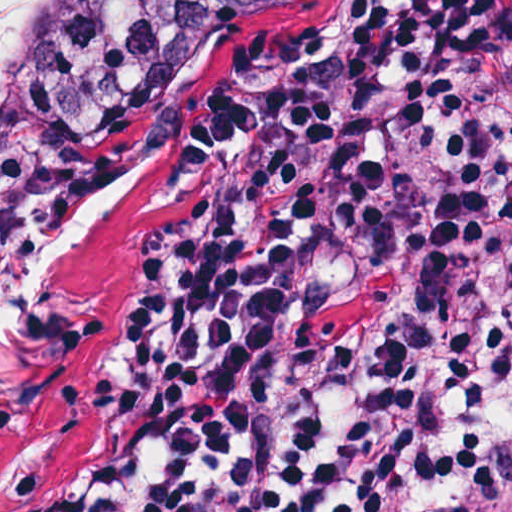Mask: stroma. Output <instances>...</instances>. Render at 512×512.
Returning <instances> with one entry per match:
<instances>
[{
    "mask_svg": "<svg viewBox=\"0 0 512 512\" xmlns=\"http://www.w3.org/2000/svg\"><path fill=\"white\" fill-rule=\"evenodd\" d=\"M411 2L334 0L241 54L180 103L115 186L0 279L12 466L27 477L79 467L122 389L161 265L278 182L253 141L255 113L300 81L357 69Z\"/></svg>",
    "mask_w": 512,
    "mask_h": 512,
    "instance_id": "1",
    "label": "stroma"
}]
</instances>
